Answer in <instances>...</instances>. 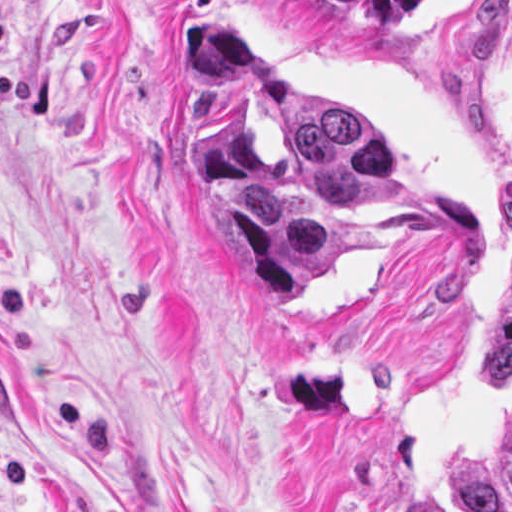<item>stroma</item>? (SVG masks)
<instances>
[{"mask_svg":"<svg viewBox=\"0 0 512 512\" xmlns=\"http://www.w3.org/2000/svg\"><path fill=\"white\" fill-rule=\"evenodd\" d=\"M358 123L393 196L293 307L189 134L183 10ZM512 262V0L375 31L298 0H0V512H458L512 418L477 313Z\"/></svg>","mask_w":512,"mask_h":512,"instance_id":"stroma-1","label":"stroma"}]
</instances>
